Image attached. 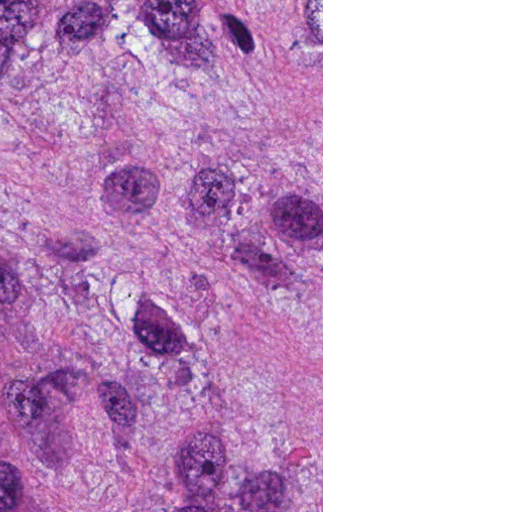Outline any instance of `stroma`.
Returning <instances> with one entry per match:
<instances>
[{
	"instance_id": "1",
	"label": "stroma",
	"mask_w": 512,
	"mask_h": 512,
	"mask_svg": "<svg viewBox=\"0 0 512 512\" xmlns=\"http://www.w3.org/2000/svg\"><path fill=\"white\" fill-rule=\"evenodd\" d=\"M161 512H323V0H161Z\"/></svg>"
}]
</instances>
